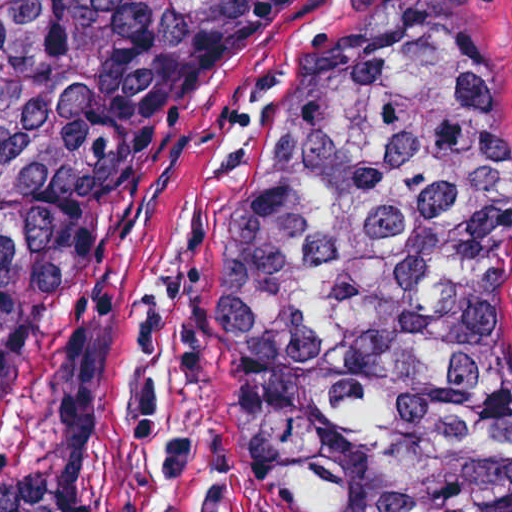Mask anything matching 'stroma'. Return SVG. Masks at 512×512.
I'll use <instances>...</instances> for the list:
<instances>
[{
    "mask_svg": "<svg viewBox=\"0 0 512 512\" xmlns=\"http://www.w3.org/2000/svg\"><path fill=\"white\" fill-rule=\"evenodd\" d=\"M450 55L512 105V0H290L154 112L103 217L107 237L4 386L0 485L58 459V357L94 307L145 271L79 512H152L167 463L174 512H272L241 450L205 322L219 225L331 63Z\"/></svg>",
    "mask_w": 512,
    "mask_h": 512,
    "instance_id": "obj_1",
    "label": "stroma"
}]
</instances>
